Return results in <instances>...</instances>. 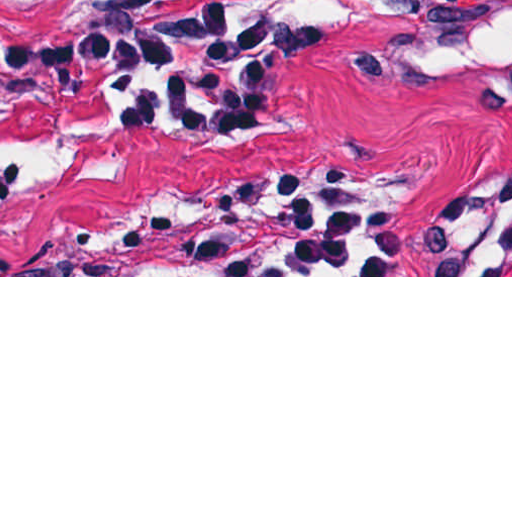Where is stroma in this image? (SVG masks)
<instances>
[{
  "label": "stroma",
  "instance_id": "obj_1",
  "mask_svg": "<svg viewBox=\"0 0 512 512\" xmlns=\"http://www.w3.org/2000/svg\"><path fill=\"white\" fill-rule=\"evenodd\" d=\"M205 0H0V277H512V102L416 74L512 0H252L292 22L270 106L225 129L88 94L14 125L31 14ZM262 87V72H261Z\"/></svg>",
  "mask_w": 512,
  "mask_h": 512
}]
</instances>
